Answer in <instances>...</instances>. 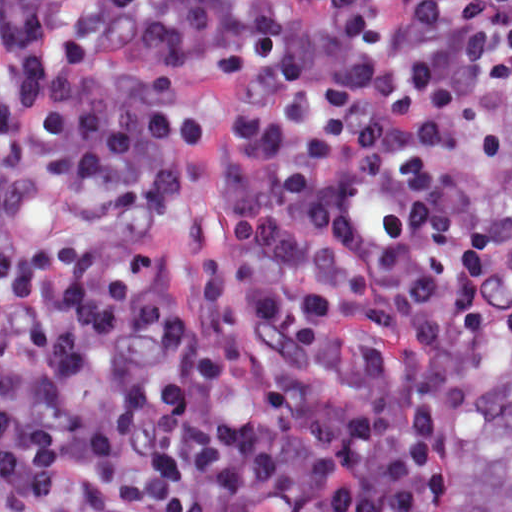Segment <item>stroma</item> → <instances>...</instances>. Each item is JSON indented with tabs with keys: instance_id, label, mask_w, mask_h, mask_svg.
Here are the masks:
<instances>
[{
	"instance_id": "obj_1",
	"label": "stroma",
	"mask_w": 512,
	"mask_h": 512,
	"mask_svg": "<svg viewBox=\"0 0 512 512\" xmlns=\"http://www.w3.org/2000/svg\"><path fill=\"white\" fill-rule=\"evenodd\" d=\"M502 126L491 151L478 195V225L482 236L492 180L508 135V101L512 93V52L503 53ZM177 103L197 112L203 128L192 141L180 187L161 213L142 231L136 244L151 252H179L192 232L200 234L209 252L218 249V225L223 204L220 144L223 133L246 111L243 75H221L205 66L182 65L174 89ZM0 512H1V0H0Z\"/></svg>"
}]
</instances>
